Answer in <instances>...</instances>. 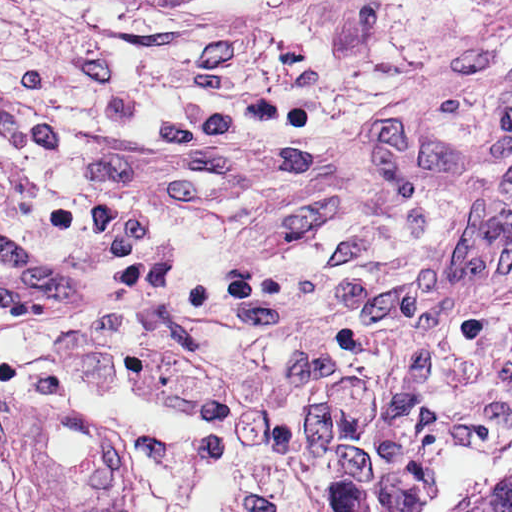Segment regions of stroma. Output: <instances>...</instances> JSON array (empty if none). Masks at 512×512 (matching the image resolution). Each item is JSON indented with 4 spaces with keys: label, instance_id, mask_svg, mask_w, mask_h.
<instances>
[{
    "label": "stroma",
    "instance_id": "1",
    "mask_svg": "<svg viewBox=\"0 0 512 512\" xmlns=\"http://www.w3.org/2000/svg\"><path fill=\"white\" fill-rule=\"evenodd\" d=\"M0 216L73 275L99 280L0 59ZM0 389L85 407L88 394L167 433L119 323H34L0 311Z\"/></svg>",
    "mask_w": 512,
    "mask_h": 512
}]
</instances>
